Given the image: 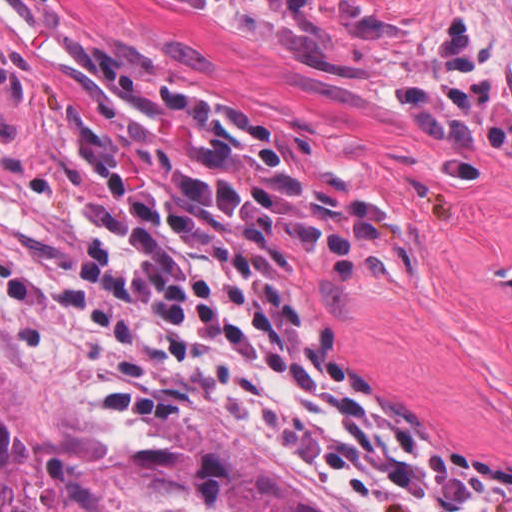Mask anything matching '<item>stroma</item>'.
<instances>
[{
	"instance_id": "stroma-1",
	"label": "stroma",
	"mask_w": 512,
	"mask_h": 512,
	"mask_svg": "<svg viewBox=\"0 0 512 512\" xmlns=\"http://www.w3.org/2000/svg\"><path fill=\"white\" fill-rule=\"evenodd\" d=\"M351 1L512 91V0ZM170 105L217 111L308 162L368 237L321 264L283 249L310 327L361 389L512 468V296L479 278L512 258V137H426L382 84L332 74L218 0H0V363L33 512H148L120 484L158 440L146 414L230 432L303 501L365 512L196 353L70 271L69 190L115 162L177 173Z\"/></svg>"
}]
</instances>
